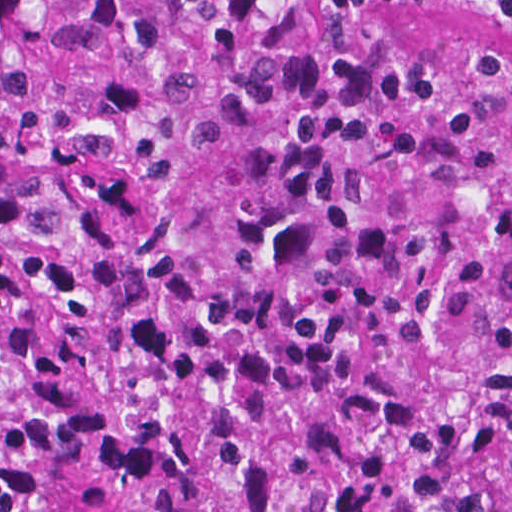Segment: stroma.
Listing matches in <instances>:
<instances>
[{
    "instance_id": "stroma-1",
    "label": "stroma",
    "mask_w": 512,
    "mask_h": 512,
    "mask_svg": "<svg viewBox=\"0 0 512 512\" xmlns=\"http://www.w3.org/2000/svg\"><path fill=\"white\" fill-rule=\"evenodd\" d=\"M275 43L314 61L326 45L339 43L420 68H458L480 57L512 68V20L446 5L294 0L276 23Z\"/></svg>"
}]
</instances>
